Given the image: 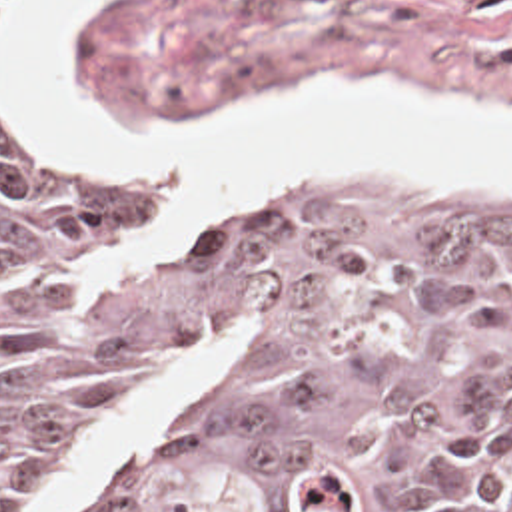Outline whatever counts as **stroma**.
Returning a JSON list of instances; mask_svg holds the SVG:
<instances>
[{
  "instance_id": "1",
  "label": "stroma",
  "mask_w": 512,
  "mask_h": 512,
  "mask_svg": "<svg viewBox=\"0 0 512 512\" xmlns=\"http://www.w3.org/2000/svg\"><path fill=\"white\" fill-rule=\"evenodd\" d=\"M22 3L0 0L8 153L58 175H118L154 193L156 223L128 263L180 255L224 217L172 231L180 199L162 177L56 157L20 123L6 59ZM76 55L94 109L110 117L216 115L320 77H382L459 107L512 115V0H92L76 21ZM294 185H334L402 211L512 215V189L382 175L256 179L228 215Z\"/></svg>"
}]
</instances>
